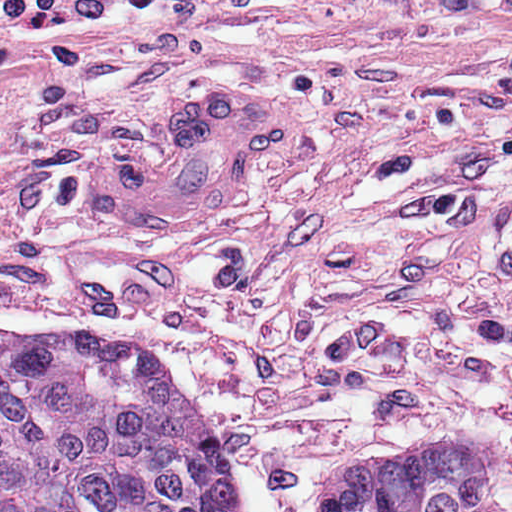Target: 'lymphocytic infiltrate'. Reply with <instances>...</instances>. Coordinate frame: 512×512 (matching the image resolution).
Segmentation results:
<instances>
[{
	"mask_svg": "<svg viewBox=\"0 0 512 512\" xmlns=\"http://www.w3.org/2000/svg\"><path fill=\"white\" fill-rule=\"evenodd\" d=\"M168 0H0V64L35 28H73L141 12Z\"/></svg>",
	"mask_w": 512,
	"mask_h": 512,
	"instance_id": "1",
	"label": "lymphocytic infiltrate"
}]
</instances>
